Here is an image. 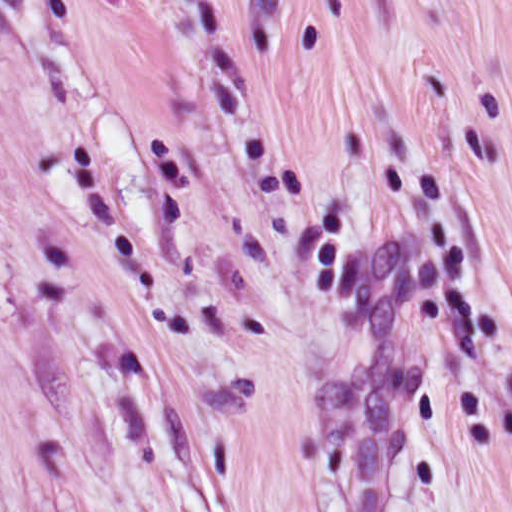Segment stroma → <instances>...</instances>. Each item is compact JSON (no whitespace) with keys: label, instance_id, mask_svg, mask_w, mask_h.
<instances>
[{"label":"stroma","instance_id":"1","mask_svg":"<svg viewBox=\"0 0 512 512\" xmlns=\"http://www.w3.org/2000/svg\"><path fill=\"white\" fill-rule=\"evenodd\" d=\"M0 512H512V0H0Z\"/></svg>","mask_w":512,"mask_h":512}]
</instances>
